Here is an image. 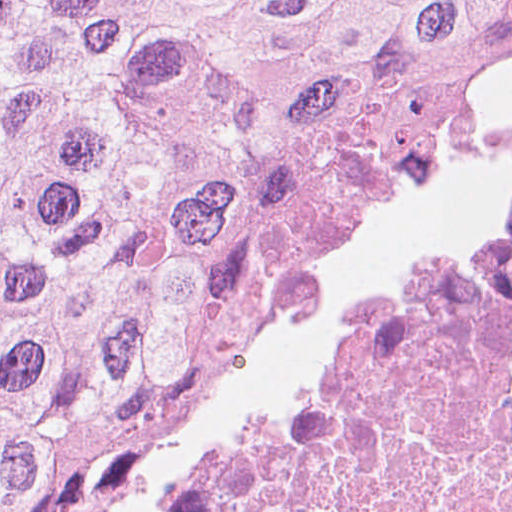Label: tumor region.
<instances>
[{
	"label": "tumor region",
	"instance_id": "obj_1",
	"mask_svg": "<svg viewBox=\"0 0 512 512\" xmlns=\"http://www.w3.org/2000/svg\"><path fill=\"white\" fill-rule=\"evenodd\" d=\"M512 124V0H1V512L252 268Z\"/></svg>",
	"mask_w": 512,
	"mask_h": 512
}]
</instances>
